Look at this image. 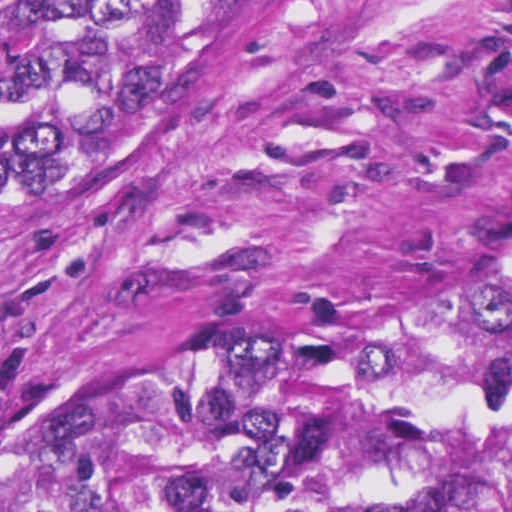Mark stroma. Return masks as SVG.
I'll list each match as a JSON object with an SVG mask.
<instances>
[{
  "label": "stroma",
  "mask_w": 512,
  "mask_h": 512,
  "mask_svg": "<svg viewBox=\"0 0 512 512\" xmlns=\"http://www.w3.org/2000/svg\"><path fill=\"white\" fill-rule=\"evenodd\" d=\"M510 222L512 0H294L218 88L0 127V465Z\"/></svg>",
  "instance_id": "35a3bbf8"
}]
</instances>
